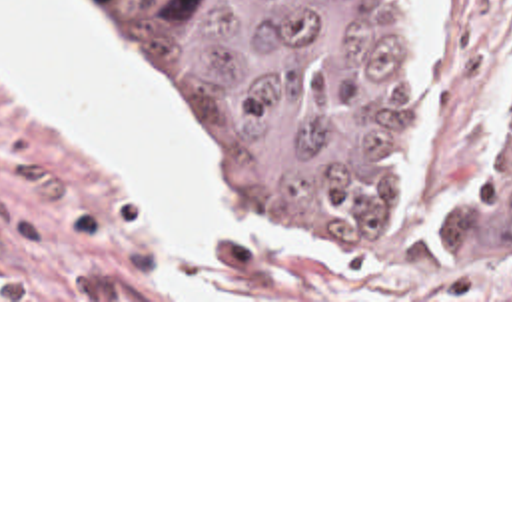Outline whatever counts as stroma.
<instances>
[{"mask_svg": "<svg viewBox=\"0 0 512 512\" xmlns=\"http://www.w3.org/2000/svg\"><path fill=\"white\" fill-rule=\"evenodd\" d=\"M102 32L154 116L192 152L215 214L213 272L192 298L160 208L102 148L16 94L0 66V302H512V284L433 256H263L209 202L192 126L168 116L102 9ZM417 68L421 116L403 202L471 186L512 126V0H389ZM431 212V208H419Z\"/></svg>", "mask_w": 512, "mask_h": 512, "instance_id": "stroma-1", "label": "stroma"}]
</instances>
